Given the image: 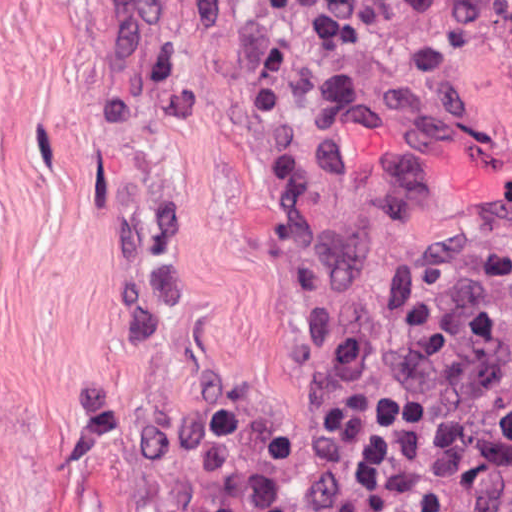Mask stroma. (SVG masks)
<instances>
[{
  "label": "stroma",
  "mask_w": 512,
  "mask_h": 512,
  "mask_svg": "<svg viewBox=\"0 0 512 512\" xmlns=\"http://www.w3.org/2000/svg\"><path fill=\"white\" fill-rule=\"evenodd\" d=\"M512 0H0V512H172L405 261L512 215Z\"/></svg>",
  "instance_id": "obj_1"
}]
</instances>
